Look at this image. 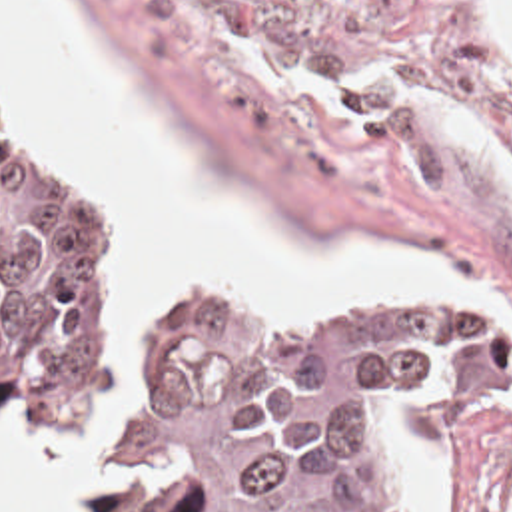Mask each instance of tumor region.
Segmentation results:
<instances>
[{"instance_id":"obj_1","label":"tumor region","mask_w":512,"mask_h":512,"mask_svg":"<svg viewBox=\"0 0 512 512\" xmlns=\"http://www.w3.org/2000/svg\"><path fill=\"white\" fill-rule=\"evenodd\" d=\"M124 261L92 187L0 145V427L76 445L98 512H389L371 425L419 445L512 399V345L463 305L253 337L182 297L124 451L100 443Z\"/></svg>"}]
</instances>
